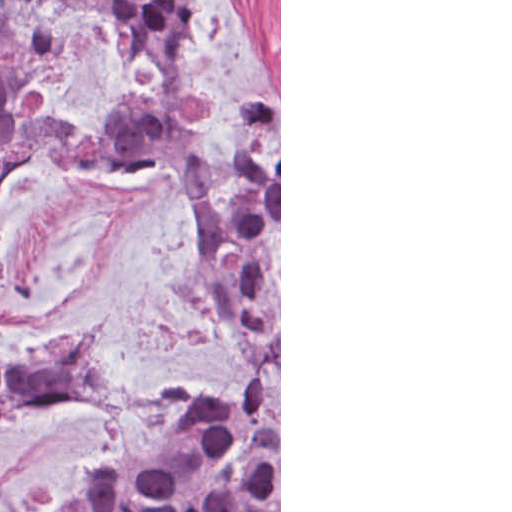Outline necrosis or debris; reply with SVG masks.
I'll use <instances>...</instances> for the list:
<instances>
[{"label":"necrosis or debris","mask_w":512,"mask_h":512,"mask_svg":"<svg viewBox=\"0 0 512 512\" xmlns=\"http://www.w3.org/2000/svg\"><path fill=\"white\" fill-rule=\"evenodd\" d=\"M19 121V93L14 86L0 76V146L14 136Z\"/></svg>","instance_id":"obj_1"}]
</instances>
